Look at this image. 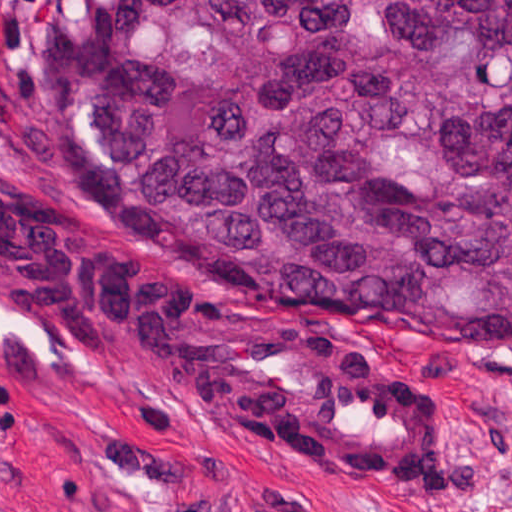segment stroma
Returning <instances> with one entry per match:
<instances>
[{"label": "stroma", "mask_w": 512, "mask_h": 512, "mask_svg": "<svg viewBox=\"0 0 512 512\" xmlns=\"http://www.w3.org/2000/svg\"><path fill=\"white\" fill-rule=\"evenodd\" d=\"M56 1L0 0V176L86 212L119 211L57 101ZM363 325L452 415L451 487L411 495L210 432L0 308V512H512V353Z\"/></svg>", "instance_id": "stroma-1"}]
</instances>
